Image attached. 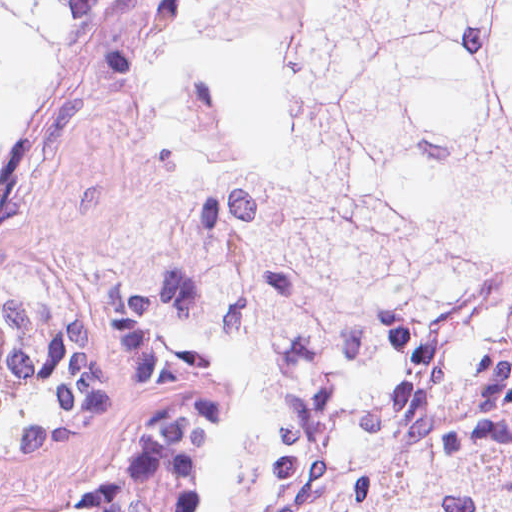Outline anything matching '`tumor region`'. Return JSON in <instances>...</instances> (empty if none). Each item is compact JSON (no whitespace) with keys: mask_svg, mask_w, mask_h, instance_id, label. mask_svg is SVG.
Returning a JSON list of instances; mask_svg holds the SVG:
<instances>
[{"mask_svg":"<svg viewBox=\"0 0 512 512\" xmlns=\"http://www.w3.org/2000/svg\"><path fill=\"white\" fill-rule=\"evenodd\" d=\"M149 3L0 1V262ZM253 39L263 123L145 242L147 341L236 394L257 512H512V1H253Z\"/></svg>","mask_w":512,"mask_h":512,"instance_id":"obj_1","label":"tumor region"}]
</instances>
